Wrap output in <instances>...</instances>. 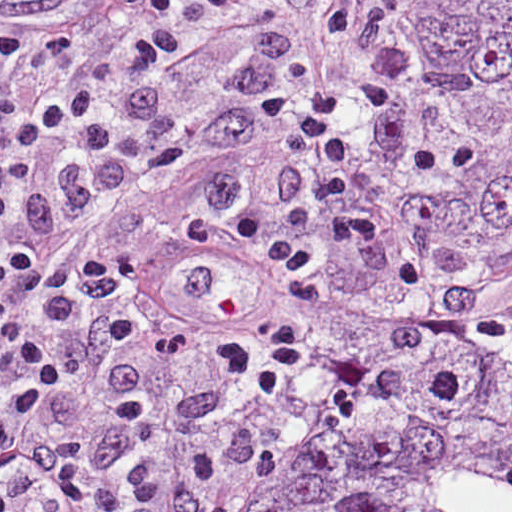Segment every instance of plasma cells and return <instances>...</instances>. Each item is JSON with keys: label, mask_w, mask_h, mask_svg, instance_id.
<instances>
[{"label": "plasma cells", "mask_w": 512, "mask_h": 512, "mask_svg": "<svg viewBox=\"0 0 512 512\" xmlns=\"http://www.w3.org/2000/svg\"><path fill=\"white\" fill-rule=\"evenodd\" d=\"M215 18H235L249 12L256 0H207Z\"/></svg>", "instance_id": "plasma-cells-1"}]
</instances>
